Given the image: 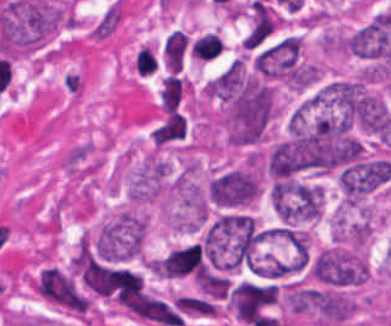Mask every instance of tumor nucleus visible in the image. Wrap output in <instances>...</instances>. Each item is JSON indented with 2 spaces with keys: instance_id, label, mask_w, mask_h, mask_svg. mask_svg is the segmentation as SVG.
Here are the masks:
<instances>
[{
  "instance_id": "obj_2",
  "label": "tumor nucleus",
  "mask_w": 391,
  "mask_h": 326,
  "mask_svg": "<svg viewBox=\"0 0 391 326\" xmlns=\"http://www.w3.org/2000/svg\"><path fill=\"white\" fill-rule=\"evenodd\" d=\"M311 272L316 279L327 283L356 284L367 278L369 266L364 252L329 246L315 257Z\"/></svg>"
},
{
  "instance_id": "obj_1",
  "label": "tumor nucleus",
  "mask_w": 391,
  "mask_h": 326,
  "mask_svg": "<svg viewBox=\"0 0 391 326\" xmlns=\"http://www.w3.org/2000/svg\"><path fill=\"white\" fill-rule=\"evenodd\" d=\"M35 291L54 307L86 315L91 299L69 268L43 264L32 278Z\"/></svg>"
},
{
  "instance_id": "obj_3",
  "label": "tumor nucleus",
  "mask_w": 391,
  "mask_h": 326,
  "mask_svg": "<svg viewBox=\"0 0 391 326\" xmlns=\"http://www.w3.org/2000/svg\"><path fill=\"white\" fill-rule=\"evenodd\" d=\"M168 165L157 152L150 151L131 170L127 180L129 203L144 204L160 200L166 195Z\"/></svg>"
},
{
  "instance_id": "obj_4",
  "label": "tumor nucleus",
  "mask_w": 391,
  "mask_h": 326,
  "mask_svg": "<svg viewBox=\"0 0 391 326\" xmlns=\"http://www.w3.org/2000/svg\"><path fill=\"white\" fill-rule=\"evenodd\" d=\"M278 286L243 282L229 297V306L234 314L247 323H254L275 300Z\"/></svg>"
}]
</instances>
